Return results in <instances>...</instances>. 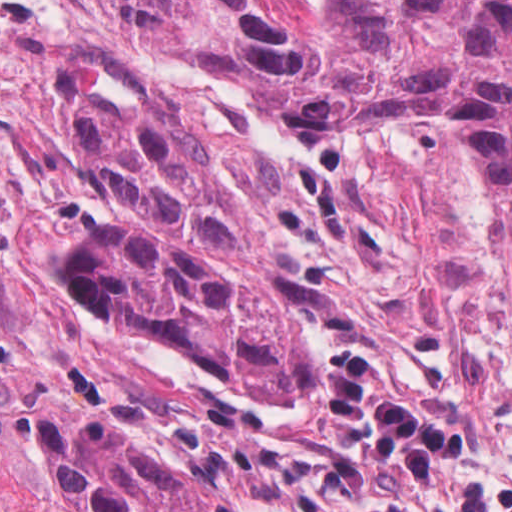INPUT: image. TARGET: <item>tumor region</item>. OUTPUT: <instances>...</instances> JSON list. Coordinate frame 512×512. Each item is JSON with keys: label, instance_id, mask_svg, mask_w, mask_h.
I'll return each mask as SVG.
<instances>
[{"label": "tumor region", "instance_id": "e687c5a6", "mask_svg": "<svg viewBox=\"0 0 512 512\" xmlns=\"http://www.w3.org/2000/svg\"><path fill=\"white\" fill-rule=\"evenodd\" d=\"M120 36L248 84L333 166L388 121H460L512 323V0H180ZM71 150L128 226L83 249L130 332L226 386L305 398L312 344L269 256L285 208L203 114L170 93L80 92Z\"/></svg>", "mask_w": 512, "mask_h": 512}]
</instances>
